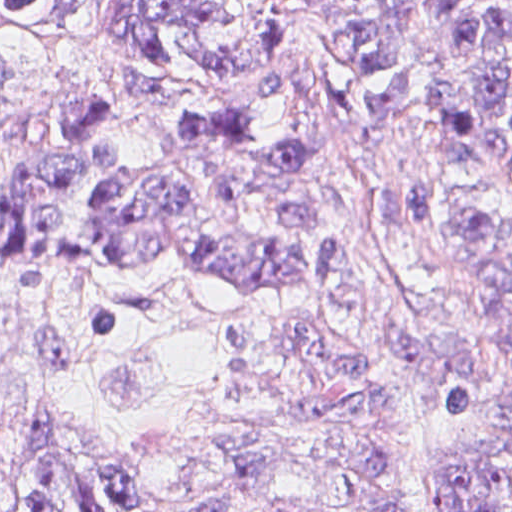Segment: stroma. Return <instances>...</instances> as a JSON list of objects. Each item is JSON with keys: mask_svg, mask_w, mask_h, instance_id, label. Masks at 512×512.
<instances>
[{"mask_svg": "<svg viewBox=\"0 0 512 512\" xmlns=\"http://www.w3.org/2000/svg\"><path fill=\"white\" fill-rule=\"evenodd\" d=\"M268 18L261 65L214 83L193 107L156 99L101 43L0 27V190L47 152L49 110L62 97L113 101L125 154L158 159L170 128L198 106H255L264 132L287 123L260 96L268 73H288L320 143L321 185L338 197L340 265L325 279L250 298L206 271L151 258L111 266L84 207L69 194L61 240L24 258L0 239V477H25L31 462L61 453L119 471L163 472L152 512L198 505L231 512H363L350 478L333 472L336 443L270 416L281 369L262 318L314 325L378 351L395 323L415 328V356L383 366L377 389L389 414L378 429L387 471L411 512H443L447 396L429 375L439 334L460 344L473 381L447 422L458 441L512 456V434L482 417L512 386L504 320L474 252V230L493 220L512 236V181L482 155L445 141L441 89L454 72L449 34L422 0H401L410 93L390 120L393 166L432 192L417 235L373 219L336 111L347 97L337 62L310 36L288 0H258ZM372 0H317L324 17ZM269 445L297 467L261 479L240 473L224 449Z\"/></svg>", "mask_w": 512, "mask_h": 512, "instance_id": "obj_1", "label": "stroma"}]
</instances>
